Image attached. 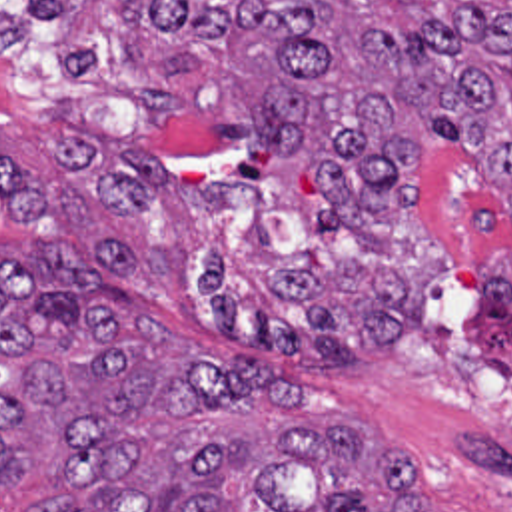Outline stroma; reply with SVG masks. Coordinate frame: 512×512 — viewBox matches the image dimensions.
Wrapping results in <instances>:
<instances>
[{
	"label": "stroma",
	"instance_id": "stroma-1",
	"mask_svg": "<svg viewBox=\"0 0 512 512\" xmlns=\"http://www.w3.org/2000/svg\"><path fill=\"white\" fill-rule=\"evenodd\" d=\"M0 6L28 20L24 44L0 54V154L20 158L50 200L10 218L0 196V256L58 240L84 258L100 232L138 254V308L166 340L262 360L298 382L314 424H350L370 445L402 447L426 512H512V358L453 262L430 286L426 322L388 354L304 362L228 336L204 292L210 248L252 294L274 270L326 272L344 258L346 228L330 236L318 220L320 174L262 142L218 134L192 102L144 128L138 94L64 74L52 12L30 0ZM414 172L461 262L493 260L497 212L467 160L426 152ZM66 495L56 473L38 469L0 485V512Z\"/></svg>",
	"mask_w": 512,
	"mask_h": 512
}]
</instances>
